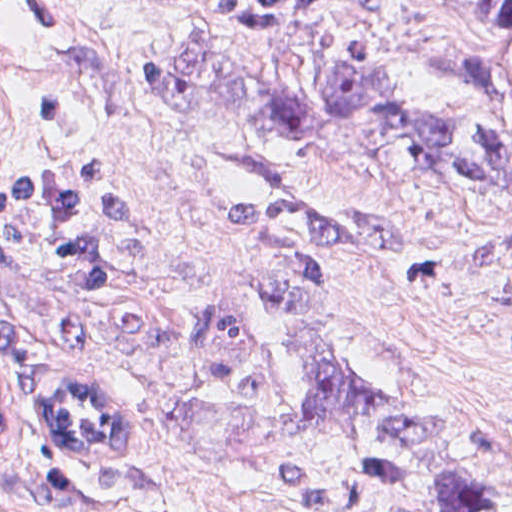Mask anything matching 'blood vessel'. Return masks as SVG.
Returning a JSON list of instances; mask_svg holds the SVG:
<instances>
[{
  "label": "blood vessel",
  "instance_id": "8fb6f2fc",
  "mask_svg": "<svg viewBox=\"0 0 512 512\" xmlns=\"http://www.w3.org/2000/svg\"><path fill=\"white\" fill-rule=\"evenodd\" d=\"M44 436L75 464L116 465L123 460L97 373L72 368L52 378Z\"/></svg>",
  "mask_w": 512,
  "mask_h": 512
}]
</instances>
